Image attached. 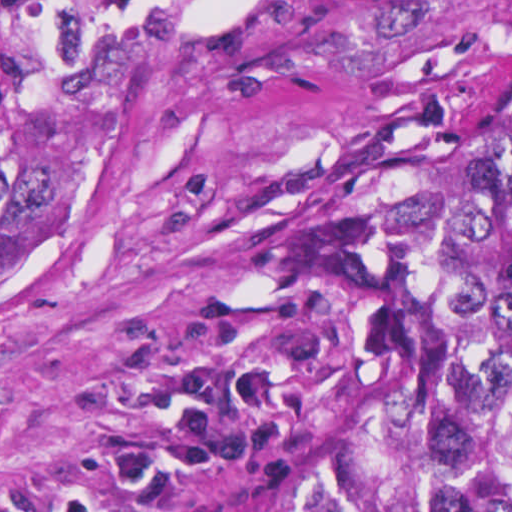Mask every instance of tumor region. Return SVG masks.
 Wrapping results in <instances>:
<instances>
[{
  "mask_svg": "<svg viewBox=\"0 0 512 512\" xmlns=\"http://www.w3.org/2000/svg\"><path fill=\"white\" fill-rule=\"evenodd\" d=\"M150 0H0V286L101 167ZM350 260L361 348L334 443L283 512H512V93L419 87Z\"/></svg>",
  "mask_w": 512,
  "mask_h": 512,
  "instance_id": "e687c5a6",
  "label": "tumor region"
}]
</instances>
